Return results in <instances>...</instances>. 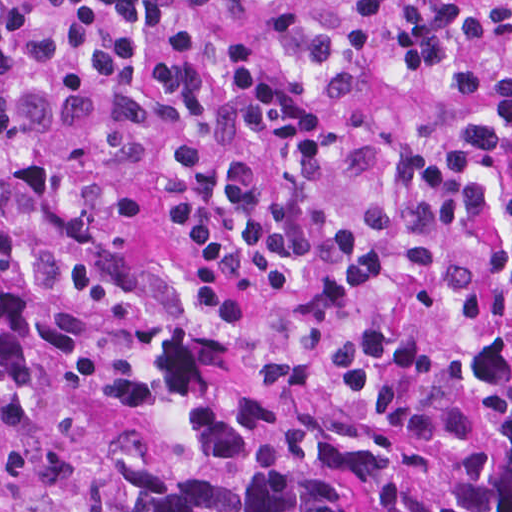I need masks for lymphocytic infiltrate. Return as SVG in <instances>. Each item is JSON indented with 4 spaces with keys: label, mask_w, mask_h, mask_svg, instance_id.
Wrapping results in <instances>:
<instances>
[{
    "label": "lymphocytic infiltrate",
    "mask_w": 512,
    "mask_h": 512,
    "mask_svg": "<svg viewBox=\"0 0 512 512\" xmlns=\"http://www.w3.org/2000/svg\"><path fill=\"white\" fill-rule=\"evenodd\" d=\"M0 190H291L512 267V0H0Z\"/></svg>",
    "instance_id": "1"
}]
</instances>
